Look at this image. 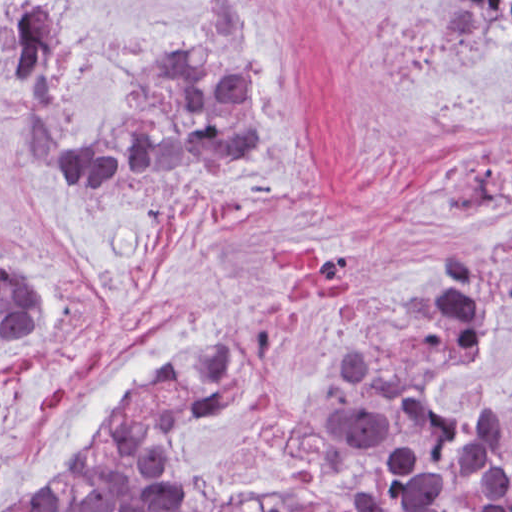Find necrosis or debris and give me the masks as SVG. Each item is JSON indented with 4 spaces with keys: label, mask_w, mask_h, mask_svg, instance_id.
<instances>
[{
    "label": "necrosis or debris",
    "mask_w": 512,
    "mask_h": 512,
    "mask_svg": "<svg viewBox=\"0 0 512 512\" xmlns=\"http://www.w3.org/2000/svg\"><path fill=\"white\" fill-rule=\"evenodd\" d=\"M511 504L506 457L482 424L361 410L332 432L316 480L212 512H509Z\"/></svg>",
    "instance_id": "obj_1"
}]
</instances>
